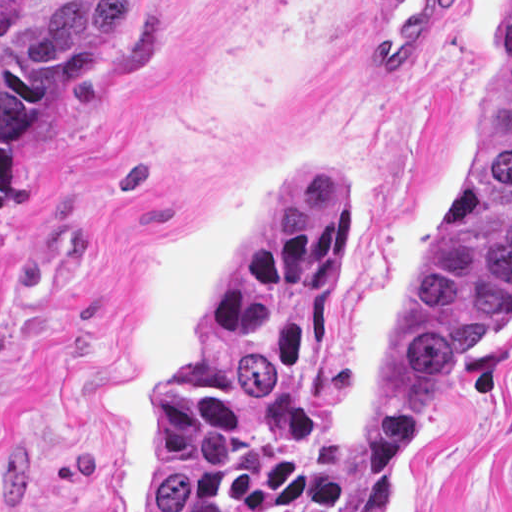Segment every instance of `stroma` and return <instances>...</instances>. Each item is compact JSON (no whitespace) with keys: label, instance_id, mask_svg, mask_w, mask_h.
<instances>
[{"label":"stroma","instance_id":"1","mask_svg":"<svg viewBox=\"0 0 512 512\" xmlns=\"http://www.w3.org/2000/svg\"><path fill=\"white\" fill-rule=\"evenodd\" d=\"M510 0H456L401 82L376 0H135L22 137L0 237V512H150L161 374L304 159L346 168L317 428L366 437L369 360L467 165ZM388 512H512V315Z\"/></svg>","mask_w":512,"mask_h":512}]
</instances>
